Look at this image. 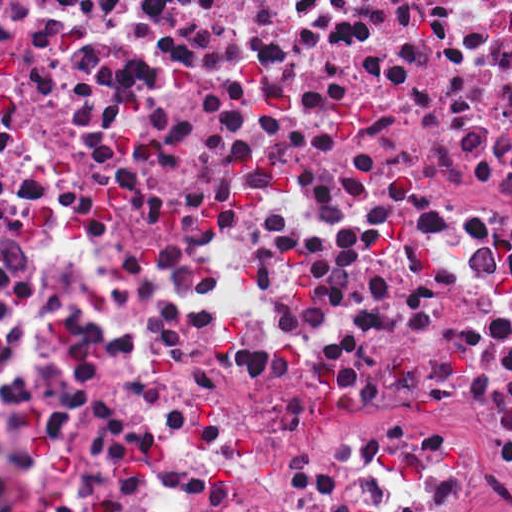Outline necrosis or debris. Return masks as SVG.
<instances>
[{"mask_svg":"<svg viewBox=\"0 0 512 512\" xmlns=\"http://www.w3.org/2000/svg\"><path fill=\"white\" fill-rule=\"evenodd\" d=\"M512 78V0H0V305Z\"/></svg>","mask_w":512,"mask_h":512,"instance_id":"obj_1","label":"necrosis or debris"}]
</instances>
